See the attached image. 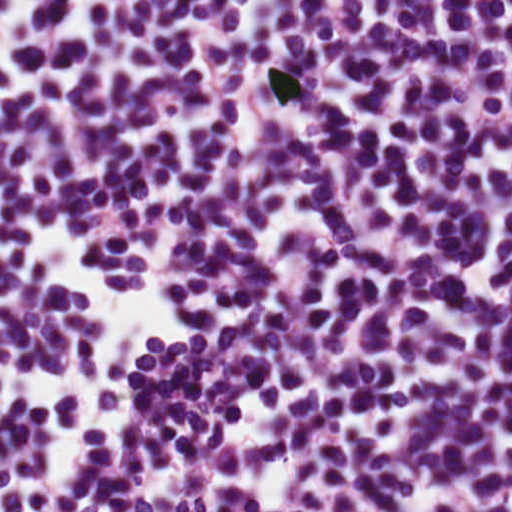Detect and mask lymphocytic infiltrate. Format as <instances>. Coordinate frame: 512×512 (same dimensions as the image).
Returning <instances> with one entry per match:
<instances>
[{
  "mask_svg": "<svg viewBox=\"0 0 512 512\" xmlns=\"http://www.w3.org/2000/svg\"><path fill=\"white\" fill-rule=\"evenodd\" d=\"M0 512H512L457 0H0Z\"/></svg>",
  "mask_w": 512,
  "mask_h": 512,
  "instance_id": "f902f5d3",
  "label": "lymphocytic infiltrate"
}]
</instances>
